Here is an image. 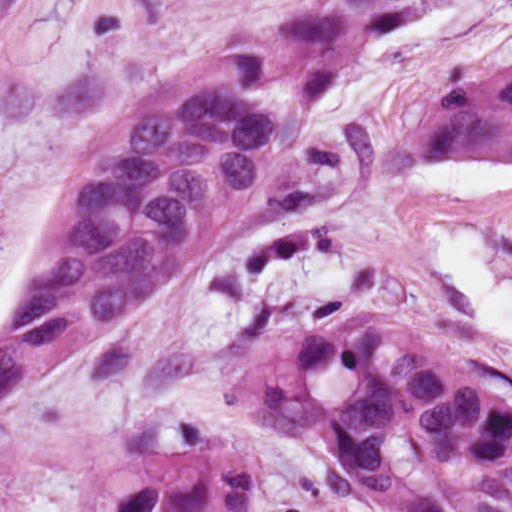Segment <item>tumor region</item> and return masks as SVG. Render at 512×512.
I'll use <instances>...</instances> for the list:
<instances>
[{"label": "tumor region", "instance_id": "e687c5a6", "mask_svg": "<svg viewBox=\"0 0 512 512\" xmlns=\"http://www.w3.org/2000/svg\"><path fill=\"white\" fill-rule=\"evenodd\" d=\"M424 0H319L151 88L74 156L28 300L0 332V434L56 349L151 308L223 239L247 190L291 153L304 120L253 93L316 102L360 43ZM425 158H512V66L426 93L410 119ZM222 389L261 430L318 451L365 512H512V407L436 343L374 317L298 335L238 363ZM255 465L186 423L168 455L97 472L74 512H249Z\"/></svg>", "mask_w": 512, "mask_h": 512}]
</instances>
